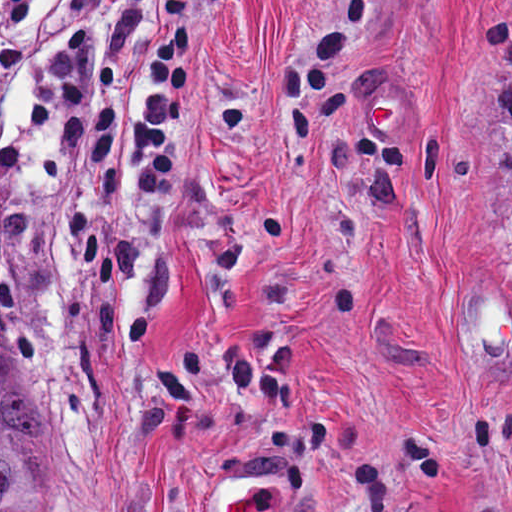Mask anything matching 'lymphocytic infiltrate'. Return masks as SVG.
I'll list each match as a JSON object with an SVG mask.
<instances>
[{
  "instance_id": "obj_1",
  "label": "lymphocytic infiltrate",
  "mask_w": 512,
  "mask_h": 512,
  "mask_svg": "<svg viewBox=\"0 0 512 512\" xmlns=\"http://www.w3.org/2000/svg\"><path fill=\"white\" fill-rule=\"evenodd\" d=\"M40 0H0V79H16L25 65V35ZM57 20L75 23L59 44L48 72L66 95L57 144L70 156L81 145L94 171L110 164L116 110L87 101L119 78V55L106 54L101 0H60ZM189 77V0H168L162 35L126 133V165L137 193L155 197L176 173V132ZM29 136L0 126V164L18 176L33 173Z\"/></svg>"
}]
</instances>
